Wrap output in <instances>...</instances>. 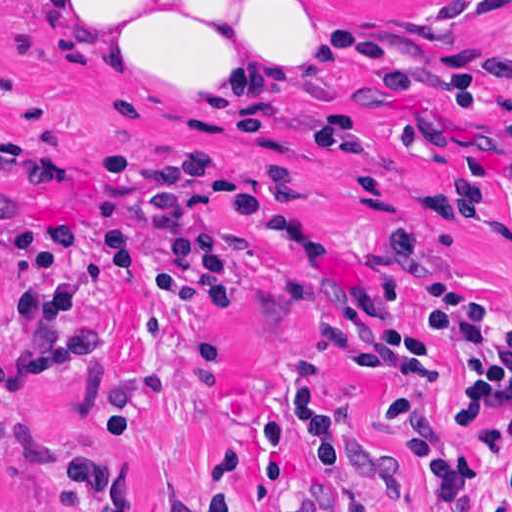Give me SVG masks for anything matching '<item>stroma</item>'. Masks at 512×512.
Here are the masks:
<instances>
[{
  "label": "stroma",
  "instance_id": "1",
  "mask_svg": "<svg viewBox=\"0 0 512 512\" xmlns=\"http://www.w3.org/2000/svg\"><path fill=\"white\" fill-rule=\"evenodd\" d=\"M320 16L406 47L417 88L400 95L366 61L345 60L318 93L272 114H219L147 98L40 44V0H0V512L24 492L40 512H74L56 462L109 460L139 512H180L205 497L228 459L248 471L245 512H278L263 480V435L283 421L297 452L291 484L314 512H355L332 492L294 412V379L317 375L338 405L380 512H439V484L383 424L404 399L431 431L464 450L489 442L455 419L459 361L435 345L436 380L368 370L324 337L359 287L399 294L411 329L432 294L396 266L393 234L415 230L436 262L499 293L512 321V32L500 87L483 117L460 116L444 87L485 46L512 0H302ZM314 81V33H313ZM335 108L359 116L361 157L319 155L281 138ZM110 142L213 148L272 191L266 216L232 243L237 300L204 308L166 282L133 278L103 246L79 239L100 360L81 373L24 377V320L10 303V219H68Z\"/></svg>",
  "mask_w": 512,
  "mask_h": 512
}]
</instances>
